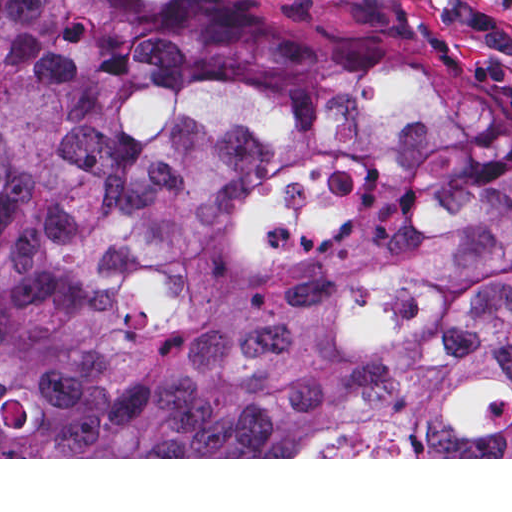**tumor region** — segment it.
I'll list each match as a JSON object with an SVG mask.
<instances>
[{"label":"tumor region","mask_w":512,"mask_h":512,"mask_svg":"<svg viewBox=\"0 0 512 512\" xmlns=\"http://www.w3.org/2000/svg\"><path fill=\"white\" fill-rule=\"evenodd\" d=\"M0 457H512V116L218 0H0Z\"/></svg>","instance_id":"obj_1"}]
</instances>
